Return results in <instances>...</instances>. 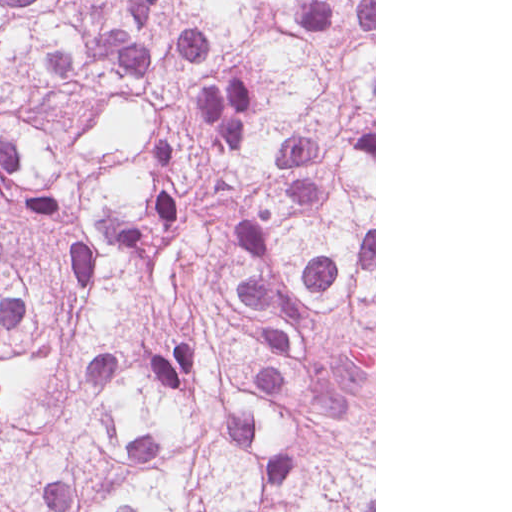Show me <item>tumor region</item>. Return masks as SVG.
Instances as JSON below:
<instances>
[{
	"instance_id": "e687c5a6",
	"label": "tumor region",
	"mask_w": 512,
	"mask_h": 512,
	"mask_svg": "<svg viewBox=\"0 0 512 512\" xmlns=\"http://www.w3.org/2000/svg\"><path fill=\"white\" fill-rule=\"evenodd\" d=\"M115 0H0V352Z\"/></svg>"
}]
</instances>
